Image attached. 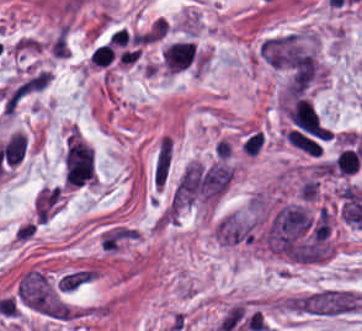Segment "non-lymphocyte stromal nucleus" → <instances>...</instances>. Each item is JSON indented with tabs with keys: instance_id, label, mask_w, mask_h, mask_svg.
Returning a JSON list of instances; mask_svg holds the SVG:
<instances>
[{
	"instance_id": "obj_3",
	"label": "non-lymphocyte stromal nucleus",
	"mask_w": 362,
	"mask_h": 331,
	"mask_svg": "<svg viewBox=\"0 0 362 331\" xmlns=\"http://www.w3.org/2000/svg\"><path fill=\"white\" fill-rule=\"evenodd\" d=\"M101 277V270L95 264L73 266L57 280L61 293H74Z\"/></svg>"
},
{
	"instance_id": "obj_1",
	"label": "non-lymphocyte stromal nucleus",
	"mask_w": 362,
	"mask_h": 331,
	"mask_svg": "<svg viewBox=\"0 0 362 331\" xmlns=\"http://www.w3.org/2000/svg\"><path fill=\"white\" fill-rule=\"evenodd\" d=\"M288 311L324 318L352 316L362 307V291L348 286H316L285 300Z\"/></svg>"
},
{
	"instance_id": "obj_2",
	"label": "non-lymphocyte stromal nucleus",
	"mask_w": 362,
	"mask_h": 331,
	"mask_svg": "<svg viewBox=\"0 0 362 331\" xmlns=\"http://www.w3.org/2000/svg\"><path fill=\"white\" fill-rule=\"evenodd\" d=\"M174 155L173 137L162 134L159 138L152 161V183L153 186L163 190L170 170L172 168Z\"/></svg>"
}]
</instances>
